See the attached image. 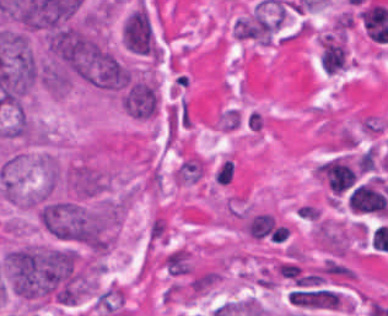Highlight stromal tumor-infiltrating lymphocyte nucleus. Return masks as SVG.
<instances>
[{
	"instance_id": "52c7bb5b",
	"label": "stromal tumor-infiltrating lymphocyte nucleus",
	"mask_w": 388,
	"mask_h": 316,
	"mask_svg": "<svg viewBox=\"0 0 388 316\" xmlns=\"http://www.w3.org/2000/svg\"><path fill=\"white\" fill-rule=\"evenodd\" d=\"M215 127L219 132H233L241 125L240 111L231 107H224L218 114Z\"/></svg>"
},
{
	"instance_id": "bc302bb0",
	"label": "stromal tumor-infiltrating lymphocyte nucleus",
	"mask_w": 388,
	"mask_h": 316,
	"mask_svg": "<svg viewBox=\"0 0 388 316\" xmlns=\"http://www.w3.org/2000/svg\"><path fill=\"white\" fill-rule=\"evenodd\" d=\"M160 267L171 278H184L192 273L188 252L182 247H175L167 252Z\"/></svg>"
}]
</instances>
